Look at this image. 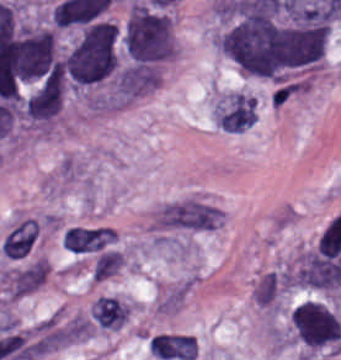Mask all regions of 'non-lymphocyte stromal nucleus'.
Wrapping results in <instances>:
<instances>
[{
    "label": "non-lymphocyte stromal nucleus",
    "mask_w": 341,
    "mask_h": 360,
    "mask_svg": "<svg viewBox=\"0 0 341 360\" xmlns=\"http://www.w3.org/2000/svg\"><path fill=\"white\" fill-rule=\"evenodd\" d=\"M152 354L164 359L194 360L197 354L195 337L189 335L160 333L151 337Z\"/></svg>",
    "instance_id": "obj_1"
},
{
    "label": "non-lymphocyte stromal nucleus",
    "mask_w": 341,
    "mask_h": 360,
    "mask_svg": "<svg viewBox=\"0 0 341 360\" xmlns=\"http://www.w3.org/2000/svg\"><path fill=\"white\" fill-rule=\"evenodd\" d=\"M61 243L67 251L72 253H83L102 248V229L68 228Z\"/></svg>",
    "instance_id": "obj_2"
}]
</instances>
